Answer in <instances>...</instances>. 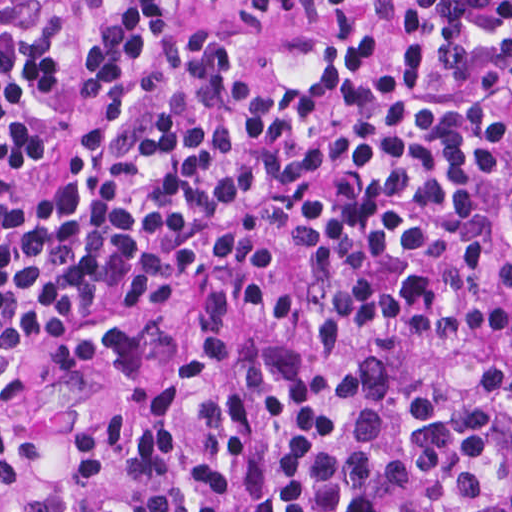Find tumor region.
<instances>
[{"instance_id":"e687c5a6","label":"tumor region","mask_w":512,"mask_h":512,"mask_svg":"<svg viewBox=\"0 0 512 512\" xmlns=\"http://www.w3.org/2000/svg\"><path fill=\"white\" fill-rule=\"evenodd\" d=\"M0 512H512V333L107 323L0 370Z\"/></svg>"}]
</instances>
